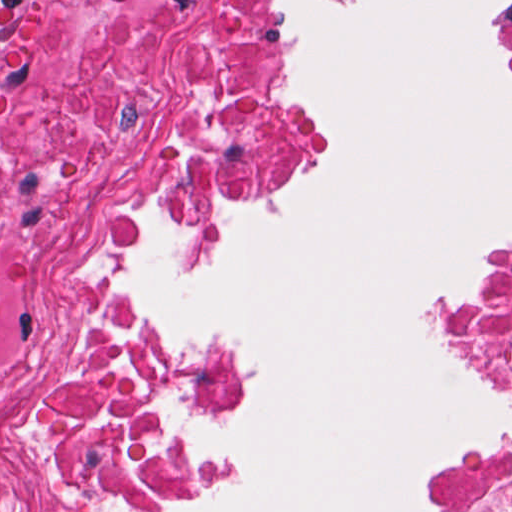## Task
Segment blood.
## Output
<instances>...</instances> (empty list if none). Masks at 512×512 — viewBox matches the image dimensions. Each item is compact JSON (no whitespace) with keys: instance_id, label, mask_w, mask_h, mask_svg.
Wrapping results in <instances>:
<instances>
[{"instance_id":"1a1defca","label":"blood","mask_w":512,"mask_h":512,"mask_svg":"<svg viewBox=\"0 0 512 512\" xmlns=\"http://www.w3.org/2000/svg\"><path fill=\"white\" fill-rule=\"evenodd\" d=\"M22 0H0V120L7 116V95L14 80V21Z\"/></svg>"}]
</instances>
